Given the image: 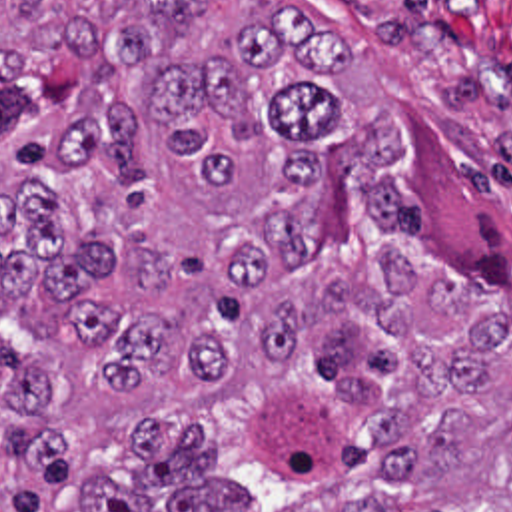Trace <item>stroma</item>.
<instances>
[{"instance_id": "1", "label": "stroma", "mask_w": 512, "mask_h": 512, "mask_svg": "<svg viewBox=\"0 0 512 512\" xmlns=\"http://www.w3.org/2000/svg\"><path fill=\"white\" fill-rule=\"evenodd\" d=\"M346 43L336 93L401 123L389 175L415 191L421 237L451 271L511 287L512 0H286ZM224 31L238 0H200Z\"/></svg>"}]
</instances>
